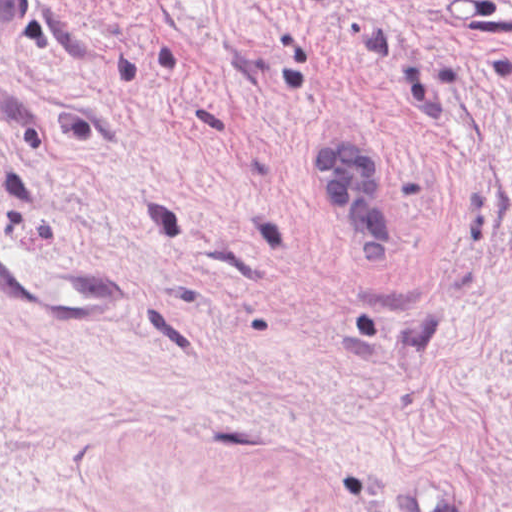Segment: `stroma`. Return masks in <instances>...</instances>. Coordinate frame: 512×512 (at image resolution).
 <instances>
[{
    "mask_svg": "<svg viewBox=\"0 0 512 512\" xmlns=\"http://www.w3.org/2000/svg\"><path fill=\"white\" fill-rule=\"evenodd\" d=\"M0 512H512V0H35L0 55Z\"/></svg>",
    "mask_w": 512,
    "mask_h": 512,
    "instance_id": "stroma-1",
    "label": "stroma"
}]
</instances>
